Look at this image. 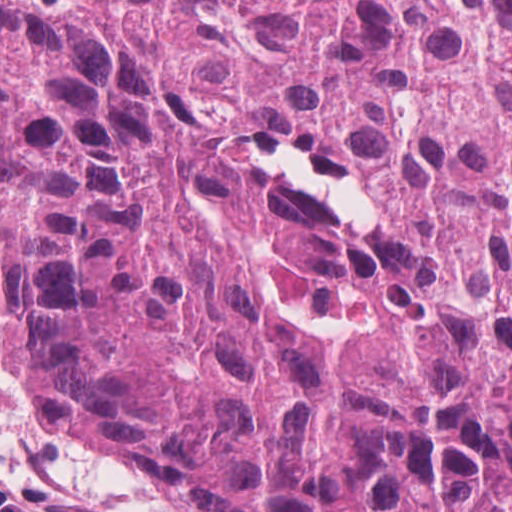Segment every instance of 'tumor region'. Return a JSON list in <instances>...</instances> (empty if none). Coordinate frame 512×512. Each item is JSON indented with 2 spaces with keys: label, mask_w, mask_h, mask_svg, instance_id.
<instances>
[{
  "label": "tumor region",
  "mask_w": 512,
  "mask_h": 512,
  "mask_svg": "<svg viewBox=\"0 0 512 512\" xmlns=\"http://www.w3.org/2000/svg\"><path fill=\"white\" fill-rule=\"evenodd\" d=\"M0 326L175 512H512V0H0Z\"/></svg>",
  "instance_id": "tumor-region-1"
}]
</instances>
